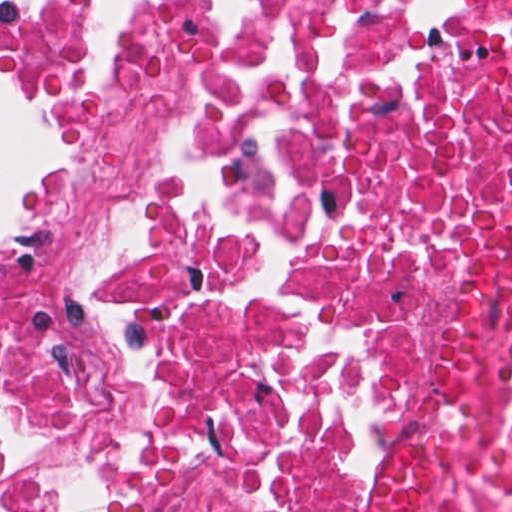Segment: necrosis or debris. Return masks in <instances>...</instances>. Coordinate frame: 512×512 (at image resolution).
<instances>
[{
    "label": "necrosis or debris",
    "instance_id": "1",
    "mask_svg": "<svg viewBox=\"0 0 512 512\" xmlns=\"http://www.w3.org/2000/svg\"><path fill=\"white\" fill-rule=\"evenodd\" d=\"M16 75L78 164L0 245V512H512V0H134Z\"/></svg>",
    "mask_w": 512,
    "mask_h": 512
}]
</instances>
